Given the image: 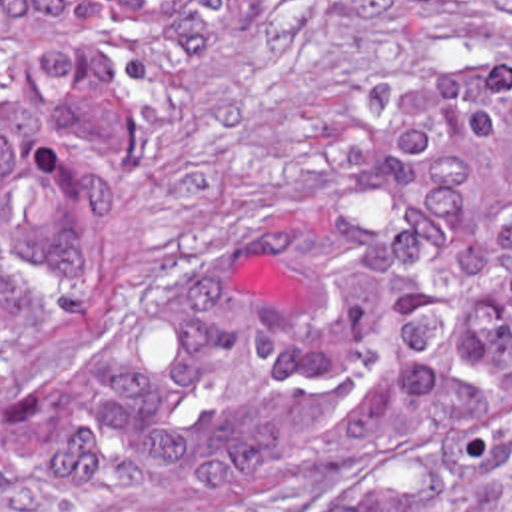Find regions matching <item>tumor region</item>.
I'll return each instance as SVG.
<instances>
[{
  "mask_svg": "<svg viewBox=\"0 0 512 512\" xmlns=\"http://www.w3.org/2000/svg\"><path fill=\"white\" fill-rule=\"evenodd\" d=\"M241 1L0 0V368L92 321L158 117ZM507 440L512 63L439 59L112 325L14 444V468L84 510Z\"/></svg>",
  "mask_w": 512,
  "mask_h": 512,
  "instance_id": "1",
  "label": "tumor region"
}]
</instances>
